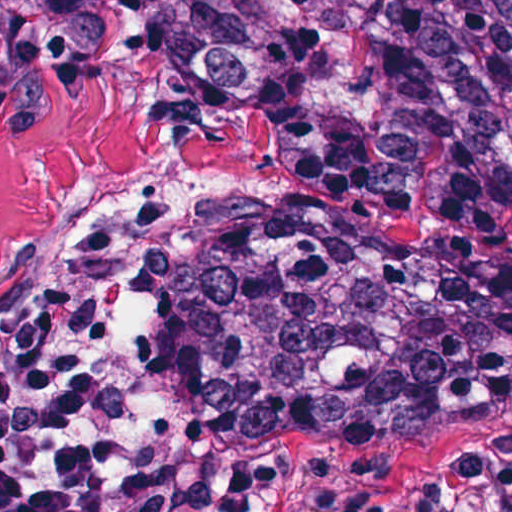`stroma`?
I'll use <instances>...</instances> for the list:
<instances>
[{"mask_svg":"<svg viewBox=\"0 0 512 512\" xmlns=\"http://www.w3.org/2000/svg\"><path fill=\"white\" fill-rule=\"evenodd\" d=\"M290 225L512 253V204L410 223L297 192L276 137L225 97L190 92L160 57L98 58L46 97L0 80V272L72 238H121V274L110 259L106 271L140 349L148 421L180 449L179 512H512V404L429 434L286 442L251 465L192 456L150 413V349L181 297L236 286Z\"/></svg>","mask_w":512,"mask_h":512,"instance_id":"35a3bbf8","label":"stroma"}]
</instances>
